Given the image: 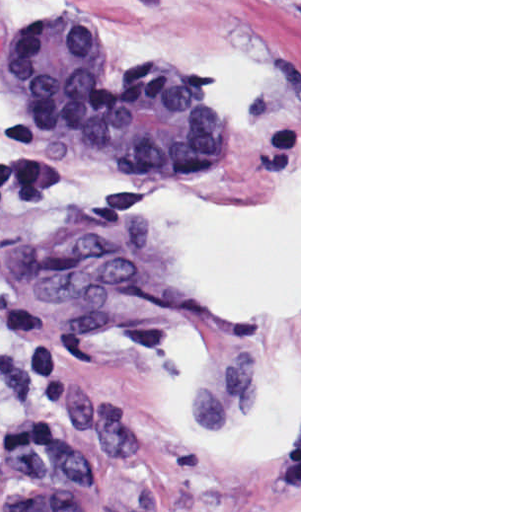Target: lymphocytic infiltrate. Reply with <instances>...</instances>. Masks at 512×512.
<instances>
[{
    "label": "lymphocytic infiltrate",
    "mask_w": 512,
    "mask_h": 512,
    "mask_svg": "<svg viewBox=\"0 0 512 512\" xmlns=\"http://www.w3.org/2000/svg\"><path fill=\"white\" fill-rule=\"evenodd\" d=\"M143 194L142 180L133 176L81 182L68 176L45 150H21L3 168L0 166V280H7L5 230L14 214L77 210L104 218L132 210ZM0 343L13 348L22 373L36 386L59 389L67 381L47 311L1 290Z\"/></svg>",
    "instance_id": "obj_1"
}]
</instances>
